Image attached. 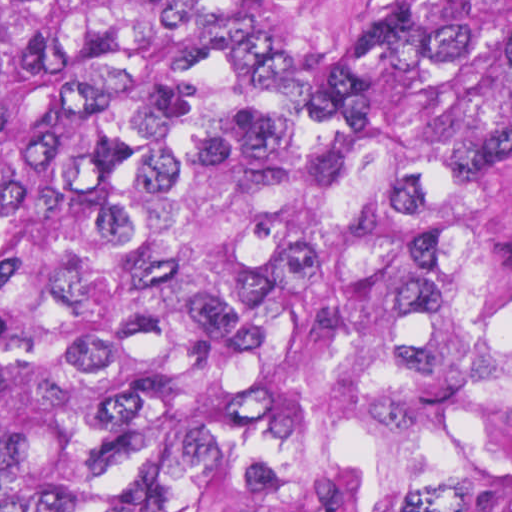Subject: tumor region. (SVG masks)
<instances>
[{"mask_svg":"<svg viewBox=\"0 0 512 512\" xmlns=\"http://www.w3.org/2000/svg\"><path fill=\"white\" fill-rule=\"evenodd\" d=\"M0 0V512H512V0Z\"/></svg>","mask_w":512,"mask_h":512,"instance_id":"obj_1","label":"tumor region"}]
</instances>
